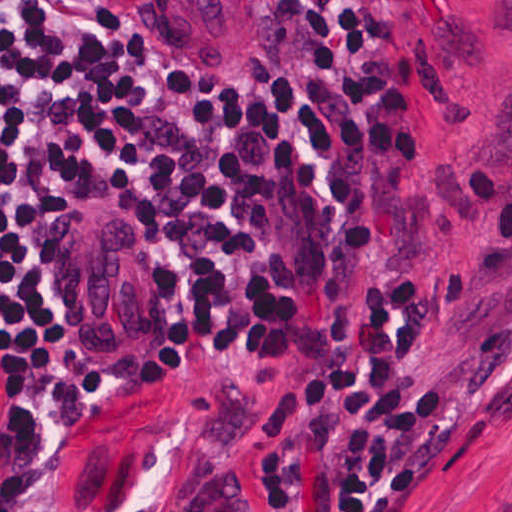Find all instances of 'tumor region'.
Listing matches in <instances>:
<instances>
[{
    "label": "tumor region",
    "mask_w": 512,
    "mask_h": 512,
    "mask_svg": "<svg viewBox=\"0 0 512 512\" xmlns=\"http://www.w3.org/2000/svg\"><path fill=\"white\" fill-rule=\"evenodd\" d=\"M134 38L182 60L251 57V11L240 0H96ZM59 293L119 365L165 367L149 251L97 204L57 228Z\"/></svg>",
    "instance_id": "1"
}]
</instances>
